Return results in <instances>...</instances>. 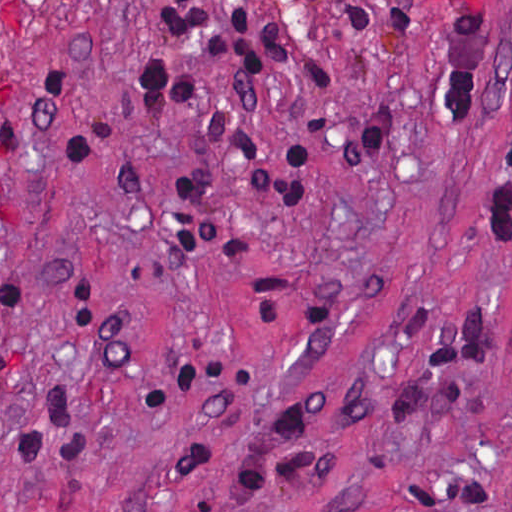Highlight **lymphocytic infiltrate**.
<instances>
[{
	"mask_svg": "<svg viewBox=\"0 0 512 512\" xmlns=\"http://www.w3.org/2000/svg\"><path fill=\"white\" fill-rule=\"evenodd\" d=\"M17 146L18 134L9 102L8 84L0 62V150L17 149Z\"/></svg>",
	"mask_w": 512,
	"mask_h": 512,
	"instance_id": "1",
	"label": "lymphocytic infiltrate"
}]
</instances>
